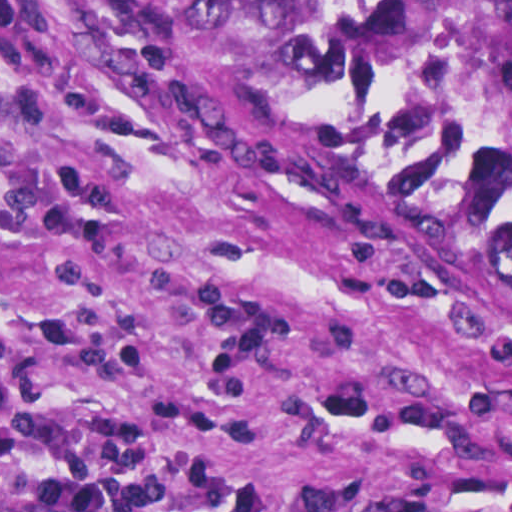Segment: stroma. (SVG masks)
I'll use <instances>...</instances> for the list:
<instances>
[{"mask_svg": "<svg viewBox=\"0 0 512 512\" xmlns=\"http://www.w3.org/2000/svg\"><path fill=\"white\" fill-rule=\"evenodd\" d=\"M126 512H512V277L69 0H0L1 470Z\"/></svg>", "mask_w": 512, "mask_h": 512, "instance_id": "1", "label": "stroma"}]
</instances>
